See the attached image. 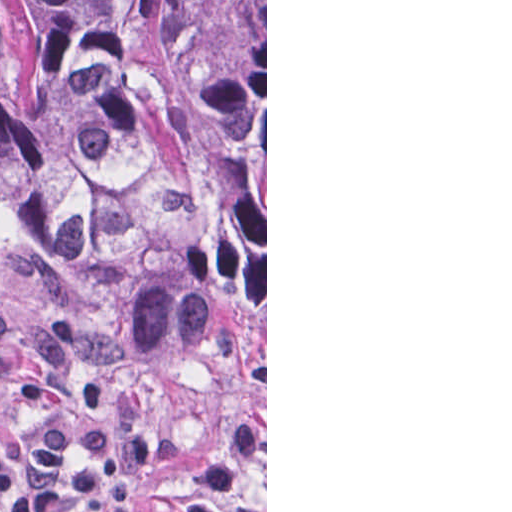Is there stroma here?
I'll return each instance as SVG.
<instances>
[{
    "label": "stroma",
    "instance_id": "1",
    "mask_svg": "<svg viewBox=\"0 0 512 512\" xmlns=\"http://www.w3.org/2000/svg\"><path fill=\"white\" fill-rule=\"evenodd\" d=\"M0 308L8 319L14 370L35 364L33 335L45 324L67 319L74 337L65 370L84 387L103 391L100 409L32 404L0 384V436L15 454L25 453L34 430L55 418L93 420L122 390L145 394L154 432L183 440L179 462H157L138 480L137 512H182L205 466L217 455L246 412L266 431V473H249L227 500V512H267V0H265V356L226 359L206 371L155 367L114 340L44 268L25 240L0 219ZM2 512V511H0ZM75 512H89L77 510Z\"/></svg>",
    "mask_w": 512,
    "mask_h": 512
}]
</instances>
